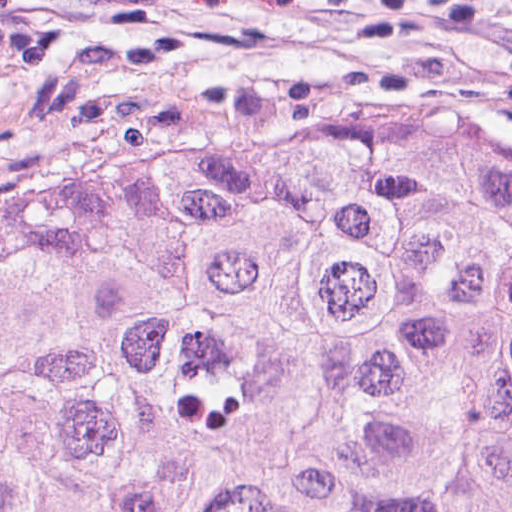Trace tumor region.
Here are the masks:
<instances>
[{"instance_id": "tumor-region-1", "label": "tumor region", "mask_w": 512, "mask_h": 512, "mask_svg": "<svg viewBox=\"0 0 512 512\" xmlns=\"http://www.w3.org/2000/svg\"><path fill=\"white\" fill-rule=\"evenodd\" d=\"M0 512H512V132L0 176Z\"/></svg>"}]
</instances>
